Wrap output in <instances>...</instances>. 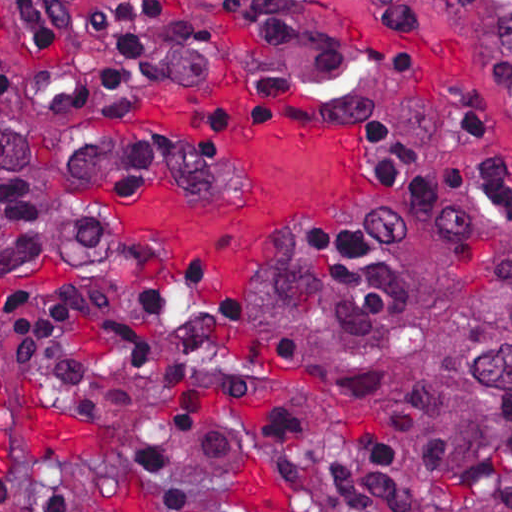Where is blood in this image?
I'll list each match as a JSON object with an SVG mask.
<instances>
[{
  "mask_svg": "<svg viewBox=\"0 0 512 512\" xmlns=\"http://www.w3.org/2000/svg\"><path fill=\"white\" fill-rule=\"evenodd\" d=\"M148 108L152 119L191 128L231 162L238 202L210 205L148 182L122 196L120 213L136 234L184 253L211 292L231 306L247 299L249 308L276 235L325 221L366 196L358 126L309 121L292 101L248 96L239 76L206 86H161Z\"/></svg>",
  "mask_w": 512,
  "mask_h": 512,
  "instance_id": "1",
  "label": "blood"
}]
</instances>
